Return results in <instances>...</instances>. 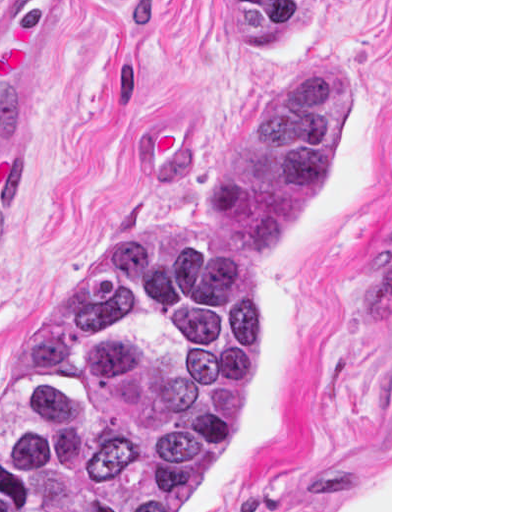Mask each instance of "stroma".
Segmentation results:
<instances>
[{
  "instance_id": "obj_1",
  "label": "stroma",
  "mask_w": 512,
  "mask_h": 512,
  "mask_svg": "<svg viewBox=\"0 0 512 512\" xmlns=\"http://www.w3.org/2000/svg\"><path fill=\"white\" fill-rule=\"evenodd\" d=\"M294 60L354 75L356 123L271 220L204 512H392V0H304L273 55L219 0H71L0 142V383L64 275L181 209Z\"/></svg>"
}]
</instances>
